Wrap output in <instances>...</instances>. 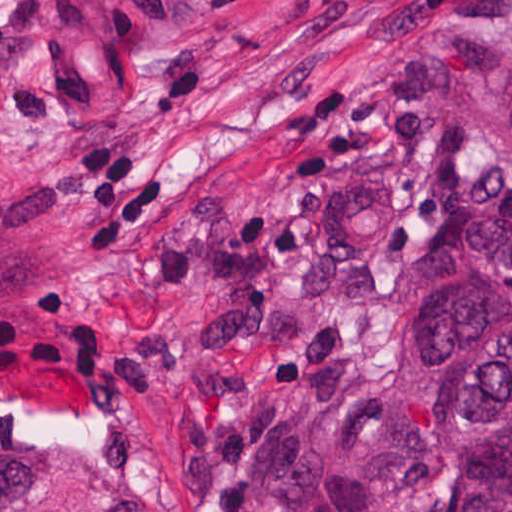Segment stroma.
<instances>
[{"instance_id": "stroma-1", "label": "stroma", "mask_w": 512, "mask_h": 512, "mask_svg": "<svg viewBox=\"0 0 512 512\" xmlns=\"http://www.w3.org/2000/svg\"><path fill=\"white\" fill-rule=\"evenodd\" d=\"M449 27L512 35V0H200L138 35L91 0H0V446L42 492L284 512L233 489L238 430L323 454L416 265L448 237L512 226V182L435 74ZM400 74L421 125L468 140V192L421 230L410 153L299 188L291 159L331 142L285 133L328 90ZM104 140L123 144L135 189L172 187L169 218L125 244L77 236L70 168Z\"/></svg>"}]
</instances>
